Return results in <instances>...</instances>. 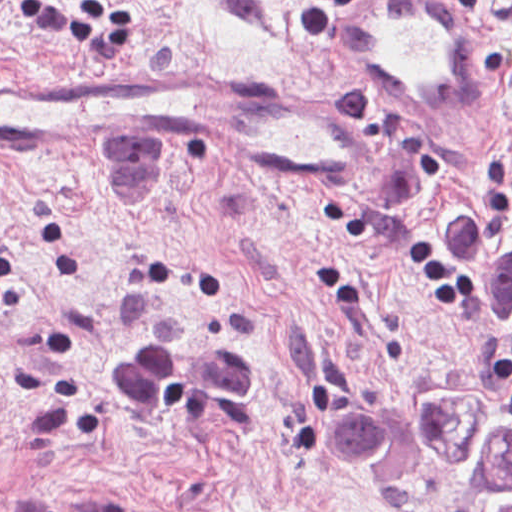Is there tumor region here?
Returning <instances> with one entry per match:
<instances>
[{
  "label": "tumor region",
  "instance_id": "e687c5a6",
  "mask_svg": "<svg viewBox=\"0 0 512 512\" xmlns=\"http://www.w3.org/2000/svg\"><path fill=\"white\" fill-rule=\"evenodd\" d=\"M444 258L478 307L488 346L512 361V207L460 203ZM469 393L345 405L326 416L324 439L385 498L415 493L440 469L478 489L486 512H512V417Z\"/></svg>",
  "mask_w": 512,
  "mask_h": 512
}]
</instances>
